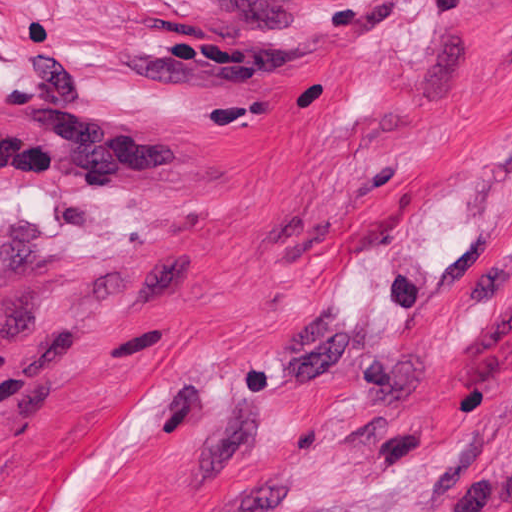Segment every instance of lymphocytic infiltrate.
Returning a JSON list of instances; mask_svg holds the SVG:
<instances>
[{
  "instance_id": "f902f5d3",
  "label": "lymphocytic infiltrate",
  "mask_w": 512,
  "mask_h": 512,
  "mask_svg": "<svg viewBox=\"0 0 512 512\" xmlns=\"http://www.w3.org/2000/svg\"><path fill=\"white\" fill-rule=\"evenodd\" d=\"M15 44L36 67L1 92L4 119L17 127L0 137V169L52 171L58 180L108 179L188 155V133L89 103L83 61L57 20L26 24Z\"/></svg>"
}]
</instances>
